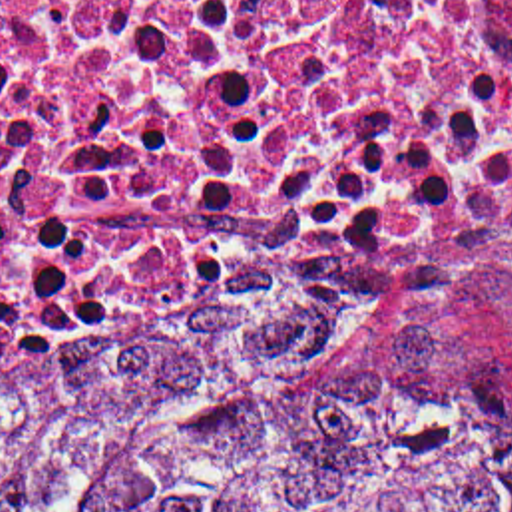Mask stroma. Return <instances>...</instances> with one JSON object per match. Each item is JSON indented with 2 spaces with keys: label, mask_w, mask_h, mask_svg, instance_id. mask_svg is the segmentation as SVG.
<instances>
[{
  "label": "stroma",
  "mask_w": 512,
  "mask_h": 512,
  "mask_svg": "<svg viewBox=\"0 0 512 512\" xmlns=\"http://www.w3.org/2000/svg\"><path fill=\"white\" fill-rule=\"evenodd\" d=\"M382 324L426 344L476 434L512 480V243Z\"/></svg>",
  "instance_id": "1"
}]
</instances>
